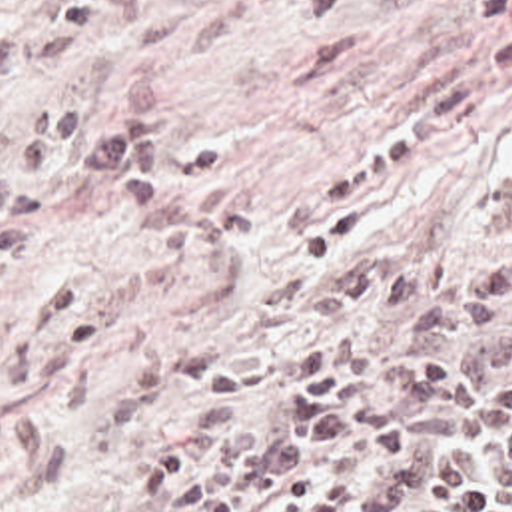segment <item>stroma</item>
Instances as JSON below:
<instances>
[{
  "label": "stroma",
  "mask_w": 512,
  "mask_h": 512,
  "mask_svg": "<svg viewBox=\"0 0 512 512\" xmlns=\"http://www.w3.org/2000/svg\"><path fill=\"white\" fill-rule=\"evenodd\" d=\"M31 0H0V25ZM512 19V0H145L139 19L63 67L65 109L151 77L171 157L143 209L49 163L31 245L0 273V512H163L141 476L185 452L199 484L265 406L205 386L339 329L313 291L379 253L467 265L509 239L512 91L407 171L303 237L277 223L379 149L425 93Z\"/></svg>",
  "instance_id": "35a3bbf8"
}]
</instances>
